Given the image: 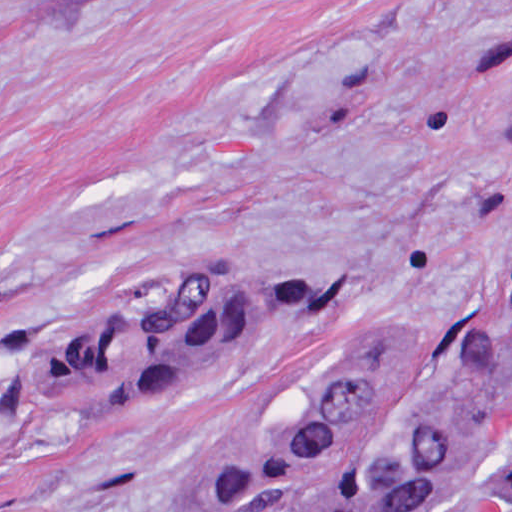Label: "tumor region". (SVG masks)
<instances>
[{"label": "tumor region", "instance_id": "obj_1", "mask_svg": "<svg viewBox=\"0 0 512 512\" xmlns=\"http://www.w3.org/2000/svg\"><path fill=\"white\" fill-rule=\"evenodd\" d=\"M333 283H243L223 265L165 304L90 320L30 367L28 403L133 416L245 336L328 308ZM512 372V215L488 319L474 337H354L335 351L300 419L227 492L223 512H437L512 499L502 449Z\"/></svg>", "mask_w": 512, "mask_h": 512}]
</instances>
